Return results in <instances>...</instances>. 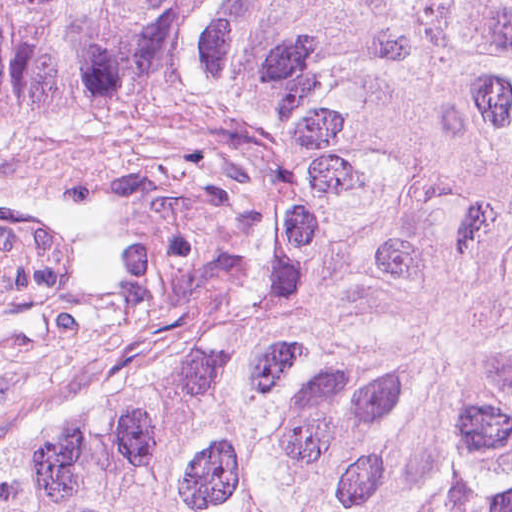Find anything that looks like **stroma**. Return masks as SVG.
I'll list each match as a JSON object with an SVG mask.
<instances>
[{"instance_id":"35a3bbf8","label":"stroma","mask_w":512,"mask_h":512,"mask_svg":"<svg viewBox=\"0 0 512 512\" xmlns=\"http://www.w3.org/2000/svg\"><path fill=\"white\" fill-rule=\"evenodd\" d=\"M264 215L237 143L0 148V445L81 419L139 360L222 366Z\"/></svg>"}]
</instances>
